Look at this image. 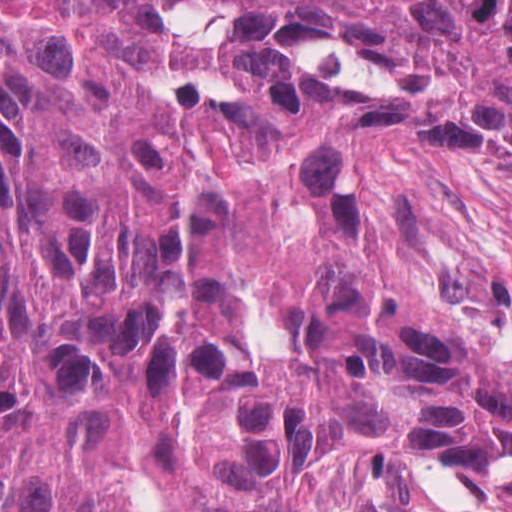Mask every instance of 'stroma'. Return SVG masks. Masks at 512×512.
Wrapping results in <instances>:
<instances>
[{"label":"stroma","mask_w":512,"mask_h":512,"mask_svg":"<svg viewBox=\"0 0 512 512\" xmlns=\"http://www.w3.org/2000/svg\"><path fill=\"white\" fill-rule=\"evenodd\" d=\"M294 512H512L486 504L464 475L383 458L328 462L294 499Z\"/></svg>","instance_id":"stroma-1"}]
</instances>
